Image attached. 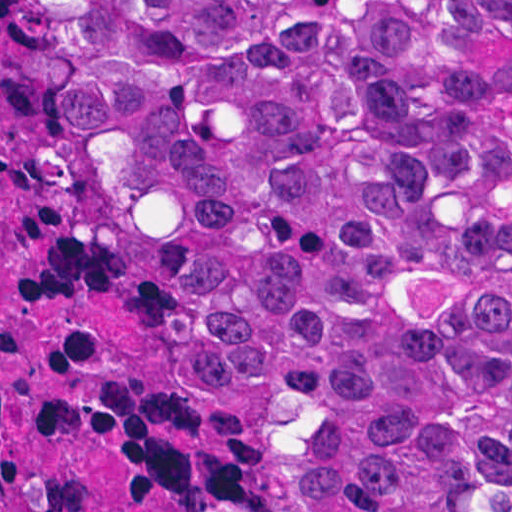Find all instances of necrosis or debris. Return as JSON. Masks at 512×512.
<instances>
[{"label":"necrosis or debris","mask_w":512,"mask_h":512,"mask_svg":"<svg viewBox=\"0 0 512 512\" xmlns=\"http://www.w3.org/2000/svg\"><path fill=\"white\" fill-rule=\"evenodd\" d=\"M0 512H315L144 152L0 0Z\"/></svg>","instance_id":"1"}]
</instances>
